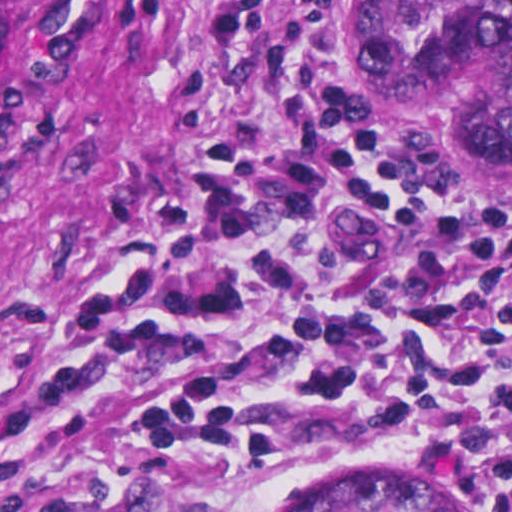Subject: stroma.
<instances>
[{
  "label": "stroma",
  "mask_w": 512,
  "mask_h": 512,
  "mask_svg": "<svg viewBox=\"0 0 512 512\" xmlns=\"http://www.w3.org/2000/svg\"><path fill=\"white\" fill-rule=\"evenodd\" d=\"M219 0H36L0 56V377L25 355L38 319L86 238L183 181L209 138L247 149L294 134L274 78V35L299 0H268L257 39L208 73ZM345 9L359 72L351 111L397 168L423 175L494 224L512 196L488 193L434 118L383 108L370 91L360 0ZM157 377L125 379L94 406L43 428L0 425V512H128L148 488L123 458L125 425ZM400 465L471 512L484 491L405 441L369 442L243 512H301L353 468Z\"/></svg>",
  "instance_id": "obj_1"
}]
</instances>
